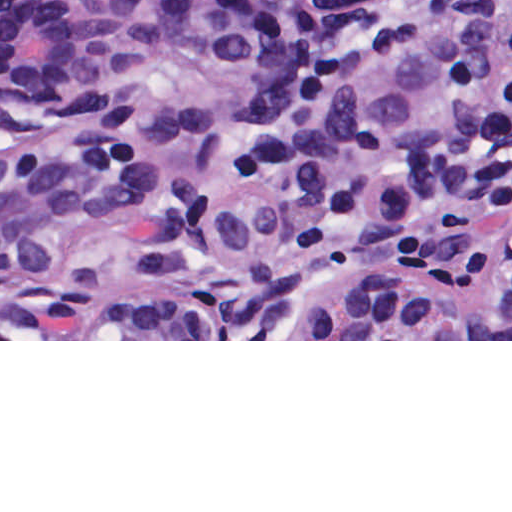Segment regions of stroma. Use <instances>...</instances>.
I'll return each mask as SVG.
<instances>
[{"instance_id":"35a3bbf8","label":"stroma","mask_w":512,"mask_h":512,"mask_svg":"<svg viewBox=\"0 0 512 512\" xmlns=\"http://www.w3.org/2000/svg\"><path fill=\"white\" fill-rule=\"evenodd\" d=\"M0 341H512V339H1V0H0Z\"/></svg>"}]
</instances>
